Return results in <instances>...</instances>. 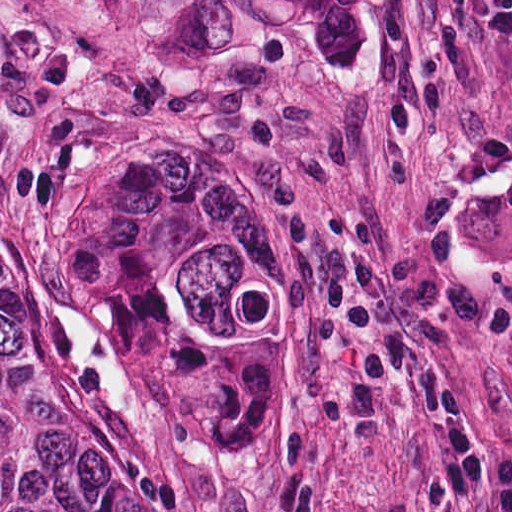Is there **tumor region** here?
I'll return each mask as SVG.
<instances>
[{"mask_svg":"<svg viewBox=\"0 0 512 512\" xmlns=\"http://www.w3.org/2000/svg\"><path fill=\"white\" fill-rule=\"evenodd\" d=\"M202 138H118L52 174L23 248L172 435H235L263 399L269 205ZM0 512H189L0 242Z\"/></svg>","mask_w":512,"mask_h":512,"instance_id":"1","label":"tumor region"}]
</instances>
